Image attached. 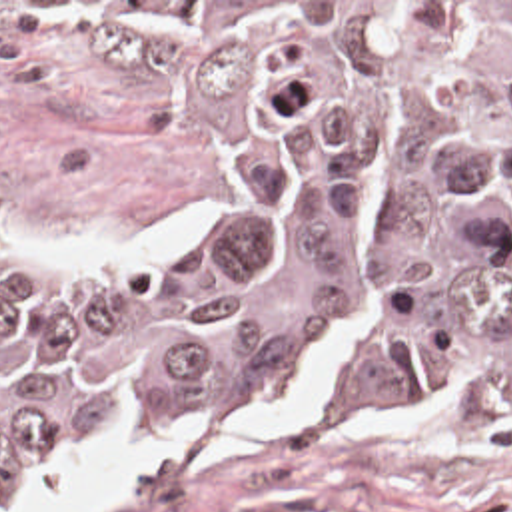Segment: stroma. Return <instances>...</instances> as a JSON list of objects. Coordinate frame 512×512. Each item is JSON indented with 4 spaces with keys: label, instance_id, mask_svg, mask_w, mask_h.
<instances>
[{
    "label": "stroma",
    "instance_id": "35a3bbf8",
    "mask_svg": "<svg viewBox=\"0 0 512 512\" xmlns=\"http://www.w3.org/2000/svg\"><path fill=\"white\" fill-rule=\"evenodd\" d=\"M64 2H512V0H0V232L100 246L192 232L146 260H36L14 274H162L208 240L236 188L214 114ZM92 512H512V435L376 431L334 411H274L224 425H146L22 469L0 512H24L32 477L72 461L176 441L260 437Z\"/></svg>",
    "mask_w": 512,
    "mask_h": 512
}]
</instances>
